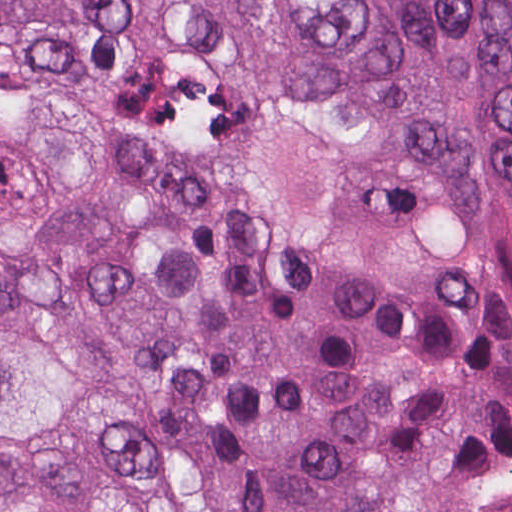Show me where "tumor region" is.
<instances>
[{"label":"tumor region","mask_w":512,"mask_h":512,"mask_svg":"<svg viewBox=\"0 0 512 512\" xmlns=\"http://www.w3.org/2000/svg\"><path fill=\"white\" fill-rule=\"evenodd\" d=\"M512 449V0H0V512H469Z\"/></svg>","instance_id":"tumor-region-1"}]
</instances>
